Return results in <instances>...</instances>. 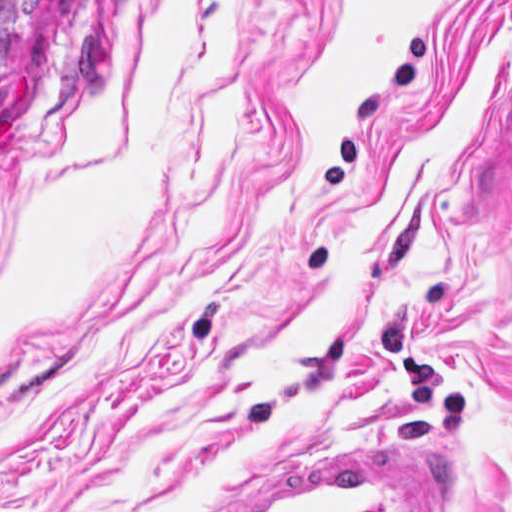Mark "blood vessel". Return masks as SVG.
I'll use <instances>...</instances> for the list:
<instances>
[{"label": "blood vessel", "mask_w": 512, "mask_h": 512, "mask_svg": "<svg viewBox=\"0 0 512 512\" xmlns=\"http://www.w3.org/2000/svg\"><path fill=\"white\" fill-rule=\"evenodd\" d=\"M272 445L181 512H455L453 456L417 434Z\"/></svg>", "instance_id": "obj_1"}]
</instances>
